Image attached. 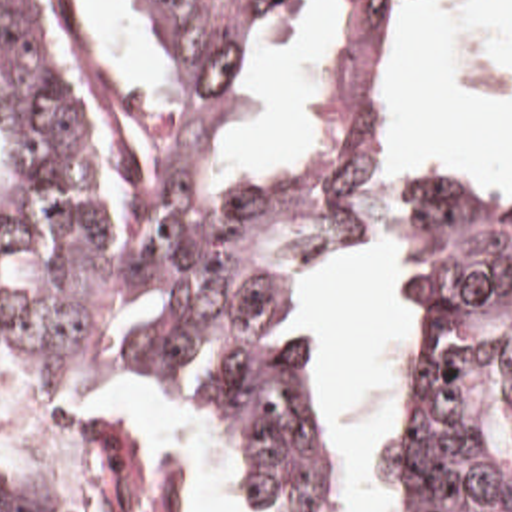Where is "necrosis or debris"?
I'll use <instances>...</instances> for the list:
<instances>
[{"mask_svg": "<svg viewBox=\"0 0 512 512\" xmlns=\"http://www.w3.org/2000/svg\"><path fill=\"white\" fill-rule=\"evenodd\" d=\"M17 448H21V446H19L17 438L13 436L11 428L7 426V422H5V418L1 416L0 412V456L11 452V450H17Z\"/></svg>", "mask_w": 512, "mask_h": 512, "instance_id": "1", "label": "necrosis or debris"}]
</instances>
